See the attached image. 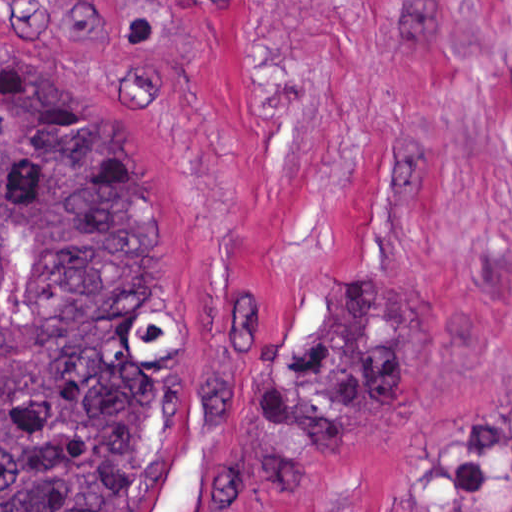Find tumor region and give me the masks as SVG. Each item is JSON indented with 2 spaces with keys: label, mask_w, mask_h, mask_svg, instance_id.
I'll list each match as a JSON object with an SVG mask.
<instances>
[{
  "label": "tumor region",
  "mask_w": 512,
  "mask_h": 512,
  "mask_svg": "<svg viewBox=\"0 0 512 512\" xmlns=\"http://www.w3.org/2000/svg\"><path fill=\"white\" fill-rule=\"evenodd\" d=\"M161 161L100 85L0 39V512H157L171 478V274ZM407 382V299L339 282L277 346L253 431L304 474ZM435 501L512 490V404L428 448Z\"/></svg>",
  "instance_id": "1"
}]
</instances>
